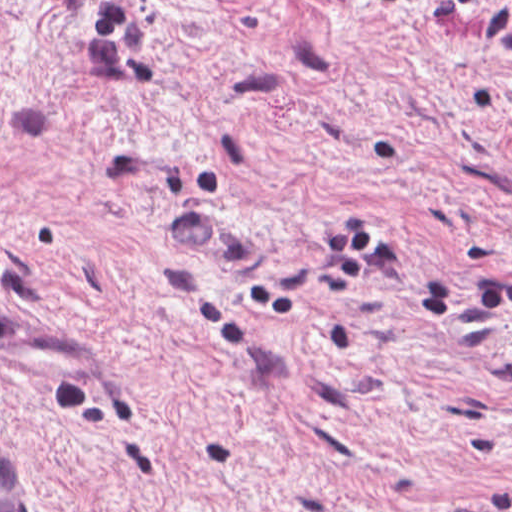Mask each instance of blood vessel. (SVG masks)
Here are the masks:
<instances>
[{
  "label": "blood vessel",
  "mask_w": 512,
  "mask_h": 512,
  "mask_svg": "<svg viewBox=\"0 0 512 512\" xmlns=\"http://www.w3.org/2000/svg\"><path fill=\"white\" fill-rule=\"evenodd\" d=\"M0 512H35V477L17 447L0 435Z\"/></svg>",
  "instance_id": "1"
}]
</instances>
